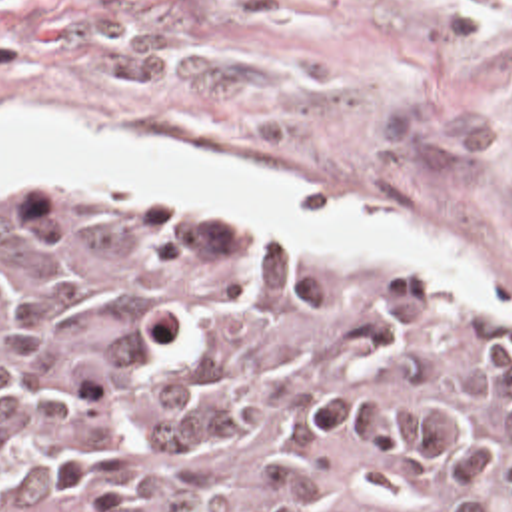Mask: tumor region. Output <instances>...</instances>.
Segmentation results:
<instances>
[{"label":"tumor region","instance_id":"e687c5a6","mask_svg":"<svg viewBox=\"0 0 512 512\" xmlns=\"http://www.w3.org/2000/svg\"><path fill=\"white\" fill-rule=\"evenodd\" d=\"M0 512H512V315L223 219L0 215Z\"/></svg>","mask_w":512,"mask_h":512}]
</instances>
